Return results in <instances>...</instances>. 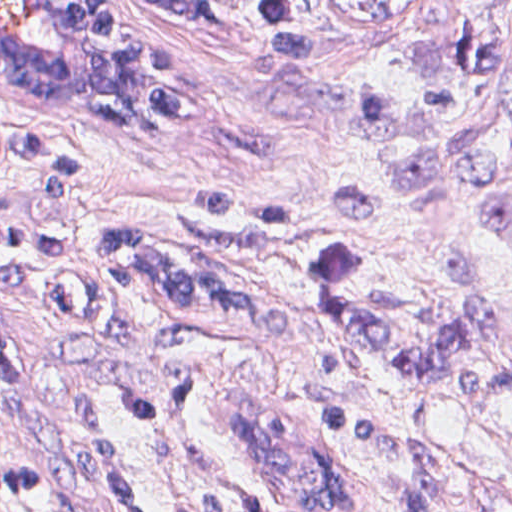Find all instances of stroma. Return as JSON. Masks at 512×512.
I'll return each mask as SVG.
<instances>
[{
	"mask_svg": "<svg viewBox=\"0 0 512 512\" xmlns=\"http://www.w3.org/2000/svg\"><path fill=\"white\" fill-rule=\"evenodd\" d=\"M121 1L179 58L171 119L101 138L0 87L80 174L41 220L0 161L16 227L67 234L0 291V512H401L419 463L512 495V235L465 158L512 127V0ZM183 213L230 330L93 258L186 256Z\"/></svg>",
	"mask_w": 512,
	"mask_h": 512,
	"instance_id": "1",
	"label": "stroma"
}]
</instances>
